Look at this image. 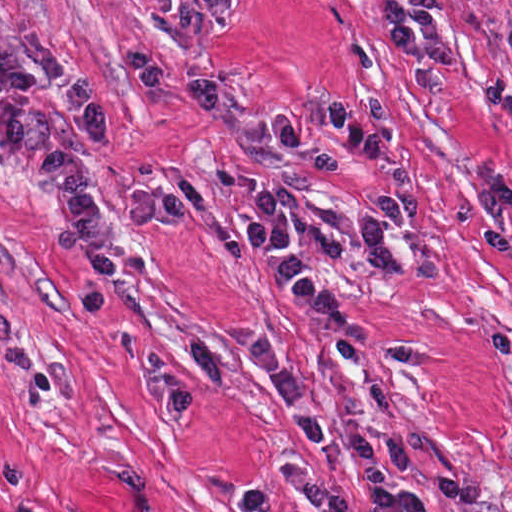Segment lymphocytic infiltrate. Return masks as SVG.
Here are the masks:
<instances>
[{
	"mask_svg": "<svg viewBox=\"0 0 512 512\" xmlns=\"http://www.w3.org/2000/svg\"><path fill=\"white\" fill-rule=\"evenodd\" d=\"M495 1V0H487ZM382 39L409 89H449L462 63L463 51L451 26L447 0H383ZM512 58V20L505 24ZM272 140L297 149L311 129L336 136L358 159L377 154V129L349 104L334 97L308 111H275L265 118ZM475 238L484 248L512 251V172H495L475 184ZM295 190L264 186L246 204L247 238L262 254L270 283L280 300L300 320L335 341H366L373 323L345 307L320 273L290 247L289 223ZM238 512H270V490L244 488L235 504Z\"/></svg>",
	"mask_w": 512,
	"mask_h": 512,
	"instance_id": "lymphocytic-infiltrate-1",
	"label": "lymphocytic infiltrate"
}]
</instances>
